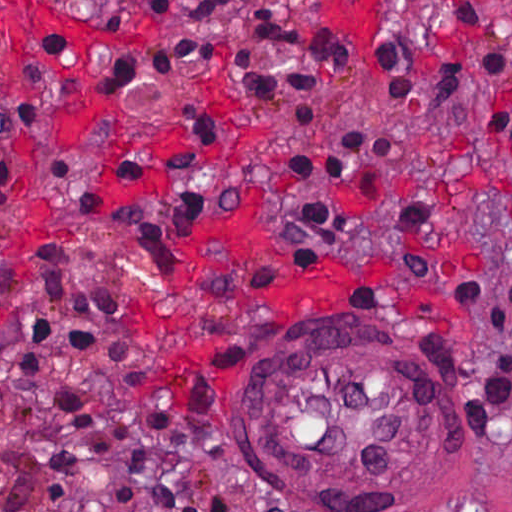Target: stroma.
Here are the masks:
<instances>
[{
  "label": "stroma",
  "mask_w": 512,
  "mask_h": 512,
  "mask_svg": "<svg viewBox=\"0 0 512 512\" xmlns=\"http://www.w3.org/2000/svg\"><path fill=\"white\" fill-rule=\"evenodd\" d=\"M74 19L121 30L147 43L95 45L78 57L66 36L46 38L51 69L27 64L32 98L14 95L9 42L0 36V115L40 104V123L25 142L0 141V164L16 175V206L0 222V351L40 354L74 367L152 410L196 452L203 468V512H512V150L477 119L478 75L458 82L435 110L431 88L449 73L459 25L442 0H284L293 28L323 24L350 45L349 71L316 83L308 128L290 120L285 92L257 102L238 71L288 66L292 52L249 42L241 27L212 22L180 37L218 48L203 70L167 76L154 93L102 92L94 84L121 57L165 49L171 31L152 24L156 0H44ZM512 60V0H481ZM1 9V5H0ZM379 37L399 40L414 56L410 101L390 105L371 62ZM201 109L218 146V203L186 241L154 268L122 235L76 215L57 182L53 160L71 162L107 201L122 200L112 177L119 152L145 158L142 190L167 189V153L181 145V114ZM385 126L397 136L389 161L342 183L307 181L290 161L338 141L344 132ZM335 199L364 247L353 258L278 217L305 200ZM260 217L280 259L300 269L343 267L360 278L342 308H286L241 286L240 263L225 257L170 303L171 317L194 322L207 364L182 389L160 390L154 370L161 334L143 308L193 241L233 214ZM61 238L71 275L87 285L131 293L100 316L90 339L7 337L30 311L54 320L38 299L29 260L33 238ZM297 308H313L300 305ZM275 309V310H273ZM380 330L405 339L440 378L448 459L432 489L393 504H338L277 480L257 442L248 439V388L257 357L292 337ZM34 445L0 429V512H16L32 480ZM74 512H138L130 487L101 467L87 479Z\"/></svg>",
  "instance_id": "1"
}]
</instances>
